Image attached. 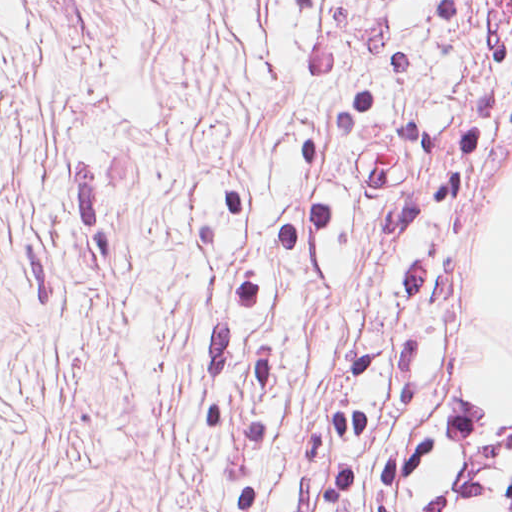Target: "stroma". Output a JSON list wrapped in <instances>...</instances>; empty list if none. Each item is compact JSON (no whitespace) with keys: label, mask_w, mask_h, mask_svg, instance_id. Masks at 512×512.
Wrapping results in <instances>:
<instances>
[{"label":"stroma","mask_w":512,"mask_h":512,"mask_svg":"<svg viewBox=\"0 0 512 512\" xmlns=\"http://www.w3.org/2000/svg\"><path fill=\"white\" fill-rule=\"evenodd\" d=\"M0 512H374L0 431Z\"/></svg>","instance_id":"35a3bbf8"}]
</instances>
